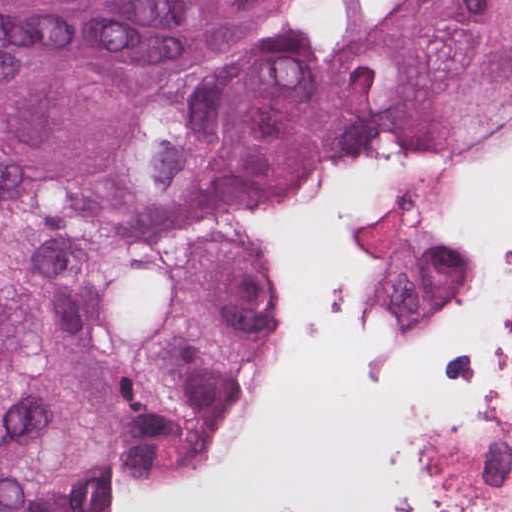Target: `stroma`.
<instances>
[{"mask_svg":"<svg viewBox=\"0 0 512 512\" xmlns=\"http://www.w3.org/2000/svg\"><path fill=\"white\" fill-rule=\"evenodd\" d=\"M512 122L468 138H504ZM368 135L332 136L286 151L244 174L227 192L253 208L266 183L302 160ZM313 268L281 291L265 354L251 378L227 439L208 443H153L137 455L141 488L136 512H166L192 492L223 481L255 459L269 434L280 401V374L292 325L306 307L320 275ZM344 365L380 369L389 359L366 356L347 324ZM417 376L429 385L460 392L452 405L432 414L403 443L401 461L411 493L425 512H512V358L467 365L423 359Z\"/></svg>","mask_w":512,"mask_h":512,"instance_id":"1","label":"stroma"}]
</instances>
